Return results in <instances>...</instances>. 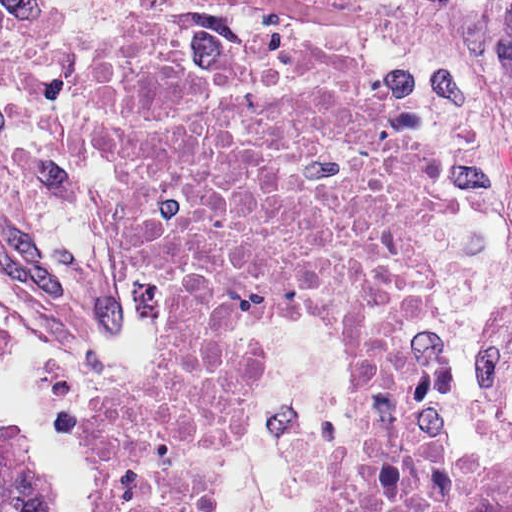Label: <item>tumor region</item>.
Instances as JSON below:
<instances>
[{"mask_svg":"<svg viewBox=\"0 0 512 512\" xmlns=\"http://www.w3.org/2000/svg\"><path fill=\"white\" fill-rule=\"evenodd\" d=\"M0 512H57L39 467L32 429L0 421Z\"/></svg>","mask_w":512,"mask_h":512,"instance_id":"1","label":"tumor region"}]
</instances>
